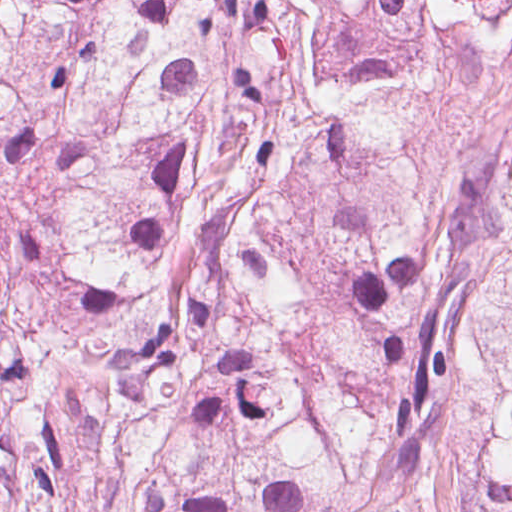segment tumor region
Instances as JSON below:
<instances>
[{
  "label": "tumor region",
  "mask_w": 512,
  "mask_h": 512,
  "mask_svg": "<svg viewBox=\"0 0 512 512\" xmlns=\"http://www.w3.org/2000/svg\"><path fill=\"white\" fill-rule=\"evenodd\" d=\"M512 0H0V512H512V125L398 115Z\"/></svg>",
  "instance_id": "e687c5a6"
}]
</instances>
